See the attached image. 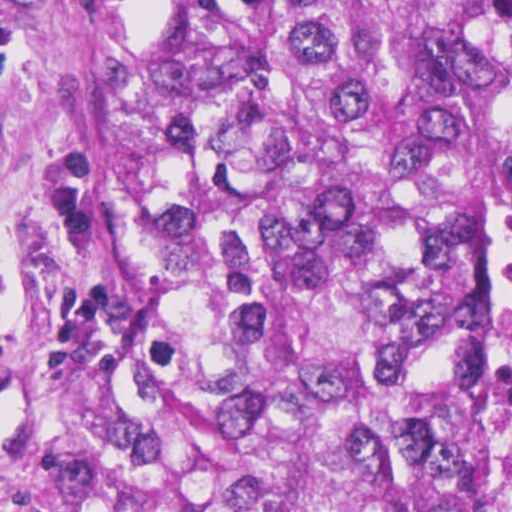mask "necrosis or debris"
Segmentation results:
<instances>
[{
    "mask_svg": "<svg viewBox=\"0 0 512 512\" xmlns=\"http://www.w3.org/2000/svg\"><path fill=\"white\" fill-rule=\"evenodd\" d=\"M490 105L495 121V243L490 270L493 512H512V11L490 75Z\"/></svg>",
    "mask_w": 512,
    "mask_h": 512,
    "instance_id": "obj_1",
    "label": "necrosis or debris"
}]
</instances>
